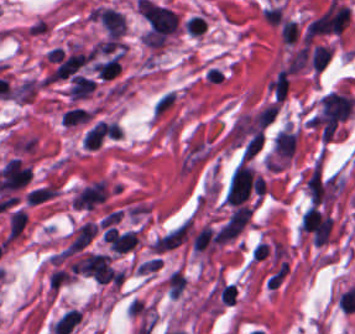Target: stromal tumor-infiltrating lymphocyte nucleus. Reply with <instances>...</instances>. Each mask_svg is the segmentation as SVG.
I'll return each instance as SVG.
<instances>
[{"label":"stromal tumor-infiltrating lymphocyte nucleus","mask_w":355,"mask_h":334,"mask_svg":"<svg viewBox=\"0 0 355 334\" xmlns=\"http://www.w3.org/2000/svg\"><path fill=\"white\" fill-rule=\"evenodd\" d=\"M176 100L175 89H167L159 93L153 101L152 114L156 117H161L169 111Z\"/></svg>","instance_id":"obj_2"},{"label":"stromal tumor-infiltrating lymphocyte nucleus","mask_w":355,"mask_h":334,"mask_svg":"<svg viewBox=\"0 0 355 334\" xmlns=\"http://www.w3.org/2000/svg\"><path fill=\"white\" fill-rule=\"evenodd\" d=\"M355 104L350 93L330 91L319 103L315 120L328 128H335Z\"/></svg>","instance_id":"obj_1"}]
</instances>
